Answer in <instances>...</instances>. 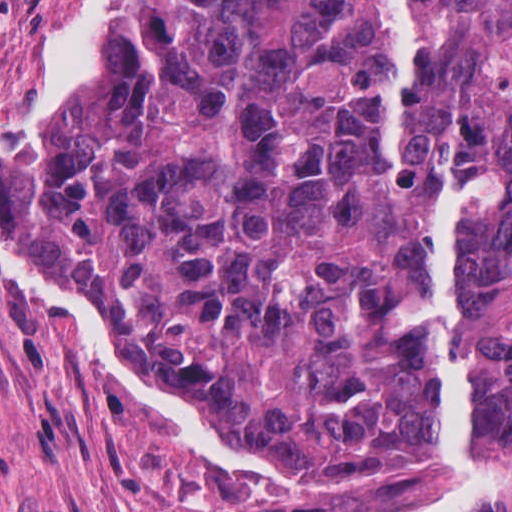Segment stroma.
Returning <instances> with one entry per match:
<instances>
[{"instance_id": "35a3bbf8", "label": "stroma", "mask_w": 512, "mask_h": 512, "mask_svg": "<svg viewBox=\"0 0 512 512\" xmlns=\"http://www.w3.org/2000/svg\"><path fill=\"white\" fill-rule=\"evenodd\" d=\"M108 0H0V137L76 71ZM447 489V473H446ZM425 469L288 479L162 409L0 244V512H420Z\"/></svg>"}]
</instances>
